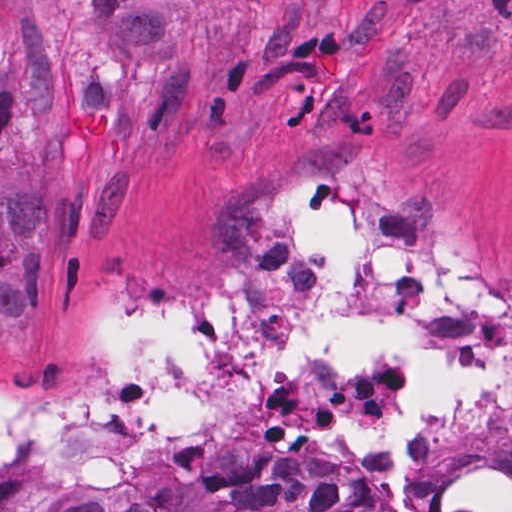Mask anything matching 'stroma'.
<instances>
[{
  "label": "stroma",
  "mask_w": 512,
  "mask_h": 512,
  "mask_svg": "<svg viewBox=\"0 0 512 512\" xmlns=\"http://www.w3.org/2000/svg\"><path fill=\"white\" fill-rule=\"evenodd\" d=\"M79 108L128 120L95 170ZM371 183L512 290V0H0V392L85 391L96 315L127 294H243L272 196ZM113 512H371L336 474L210 470Z\"/></svg>",
  "instance_id": "35a3bbf8"
}]
</instances>
